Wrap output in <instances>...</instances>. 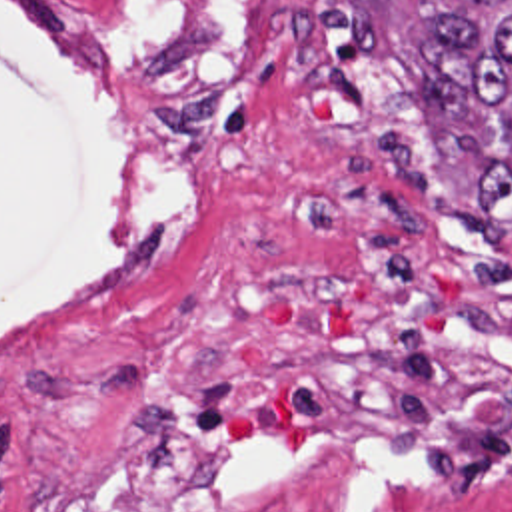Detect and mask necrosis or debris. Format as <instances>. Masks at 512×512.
Instances as JSON below:
<instances>
[{
  "label": "necrosis or debris",
  "instance_id": "1",
  "mask_svg": "<svg viewBox=\"0 0 512 512\" xmlns=\"http://www.w3.org/2000/svg\"><path fill=\"white\" fill-rule=\"evenodd\" d=\"M112 128L210 152L234 56L286 130L276 274L190 286L86 449L0 425V512H276L356 461L512 507V266L470 242L390 0H0Z\"/></svg>",
  "mask_w": 512,
  "mask_h": 512
}]
</instances>
